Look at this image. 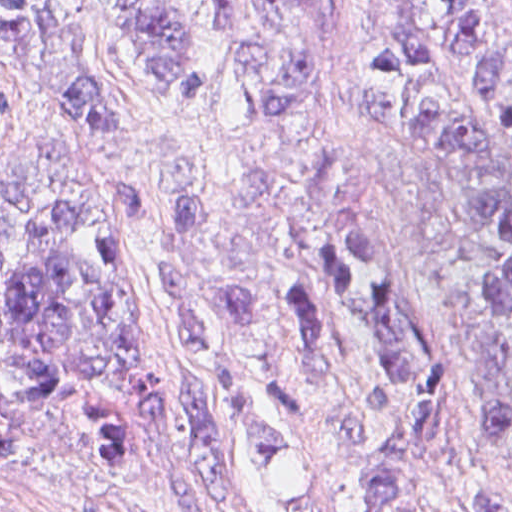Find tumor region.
I'll return each mask as SVG.
<instances>
[{
  "mask_svg": "<svg viewBox=\"0 0 512 512\" xmlns=\"http://www.w3.org/2000/svg\"><path fill=\"white\" fill-rule=\"evenodd\" d=\"M97 1L162 90L192 80L194 0ZM207 1L251 136L230 138V170L165 150L157 200L99 178L127 127L87 68L91 0H0V43L58 130L0 167V454L35 426L110 469L181 415L225 512H442L424 463L452 365L309 1ZM360 123L434 158L480 262L504 380L478 462L512 490V23L489 0H380ZM163 212L159 286L201 383L151 380L123 299L122 259Z\"/></svg>",
  "mask_w": 512,
  "mask_h": 512,
  "instance_id": "tumor-region-1",
  "label": "tumor region"
}]
</instances>
